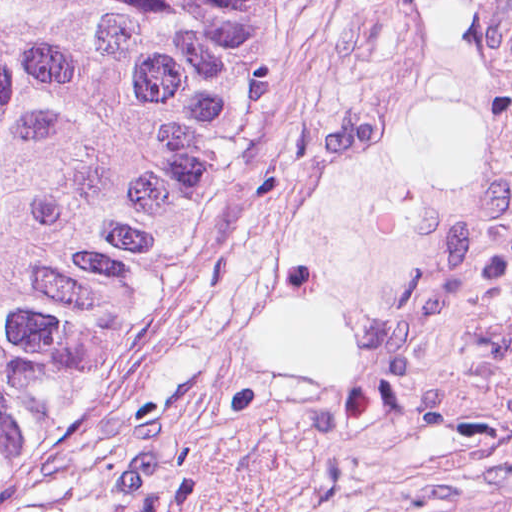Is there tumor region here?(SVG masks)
Masks as SVG:
<instances>
[{"mask_svg": "<svg viewBox=\"0 0 512 512\" xmlns=\"http://www.w3.org/2000/svg\"><path fill=\"white\" fill-rule=\"evenodd\" d=\"M285 4L0 0V512H22L136 355L148 284Z\"/></svg>", "mask_w": 512, "mask_h": 512, "instance_id": "obj_1", "label": "tumor region"}]
</instances>
